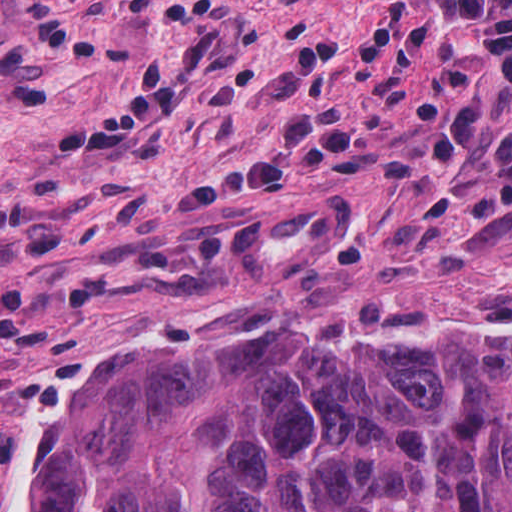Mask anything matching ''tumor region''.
Segmentation results:
<instances>
[{"mask_svg": "<svg viewBox=\"0 0 512 512\" xmlns=\"http://www.w3.org/2000/svg\"><path fill=\"white\" fill-rule=\"evenodd\" d=\"M14 512H512V249H423L347 312L255 280L113 350Z\"/></svg>", "mask_w": 512, "mask_h": 512, "instance_id": "tumor-region-1", "label": "tumor region"}]
</instances>
